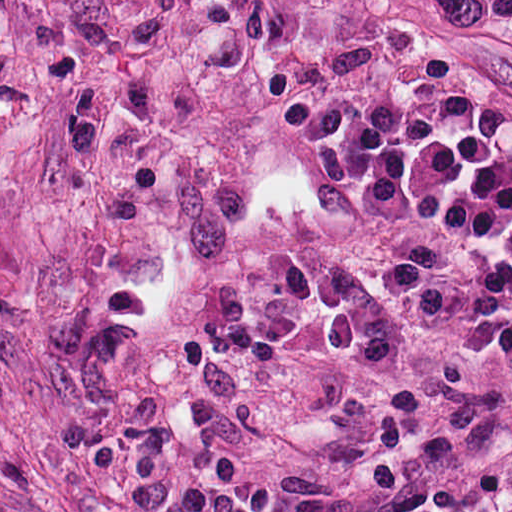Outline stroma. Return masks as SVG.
Here are the masks:
<instances>
[{
  "label": "stroma",
  "mask_w": 512,
  "mask_h": 512,
  "mask_svg": "<svg viewBox=\"0 0 512 512\" xmlns=\"http://www.w3.org/2000/svg\"><path fill=\"white\" fill-rule=\"evenodd\" d=\"M394 240L494 252L0 91V512H512L501 372L372 289Z\"/></svg>",
  "instance_id": "obj_1"
}]
</instances>
